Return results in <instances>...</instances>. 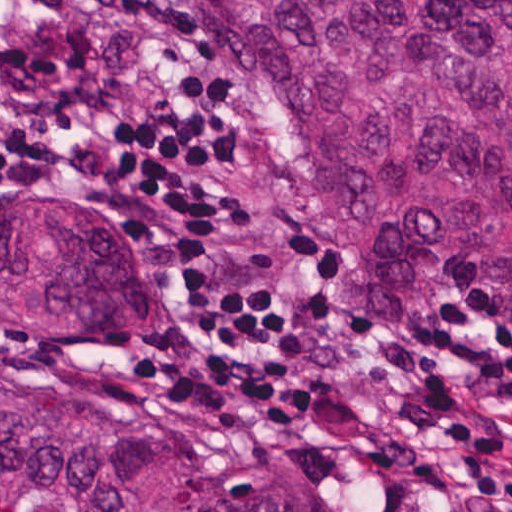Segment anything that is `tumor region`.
<instances>
[{
	"mask_svg": "<svg viewBox=\"0 0 512 512\" xmlns=\"http://www.w3.org/2000/svg\"><path fill=\"white\" fill-rule=\"evenodd\" d=\"M299 170L363 306L417 312L512 266V0H173ZM137 242L0 208V307L158 317ZM0 512H315L161 420L60 381L0 317Z\"/></svg>",
	"mask_w": 512,
	"mask_h": 512,
	"instance_id": "1",
	"label": "tumor region"
}]
</instances>
